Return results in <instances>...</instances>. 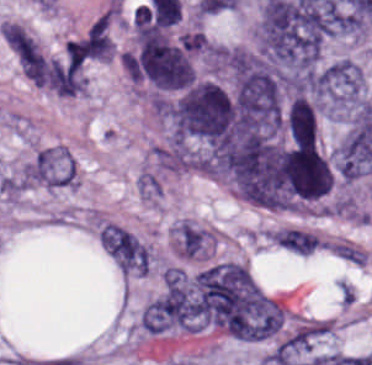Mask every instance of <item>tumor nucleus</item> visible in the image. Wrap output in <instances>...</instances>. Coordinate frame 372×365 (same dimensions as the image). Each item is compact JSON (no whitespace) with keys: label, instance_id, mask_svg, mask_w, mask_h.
I'll return each mask as SVG.
<instances>
[{"label":"tumor nucleus","instance_id":"obj_1","mask_svg":"<svg viewBox=\"0 0 372 365\" xmlns=\"http://www.w3.org/2000/svg\"><path fill=\"white\" fill-rule=\"evenodd\" d=\"M160 115L176 142L217 145L240 129L232 93L204 78L160 99Z\"/></svg>","mask_w":372,"mask_h":365},{"label":"tumor nucleus","instance_id":"obj_2","mask_svg":"<svg viewBox=\"0 0 372 365\" xmlns=\"http://www.w3.org/2000/svg\"><path fill=\"white\" fill-rule=\"evenodd\" d=\"M127 74L159 89H176L190 82L192 66L161 30L140 25L128 56Z\"/></svg>","mask_w":372,"mask_h":365},{"label":"tumor nucleus","instance_id":"obj_3","mask_svg":"<svg viewBox=\"0 0 372 365\" xmlns=\"http://www.w3.org/2000/svg\"><path fill=\"white\" fill-rule=\"evenodd\" d=\"M312 97L323 109H348L364 101V78L360 70L345 59L314 72Z\"/></svg>","mask_w":372,"mask_h":365}]
</instances>
